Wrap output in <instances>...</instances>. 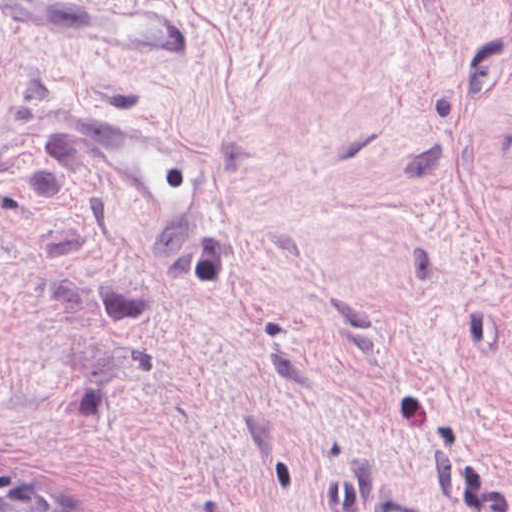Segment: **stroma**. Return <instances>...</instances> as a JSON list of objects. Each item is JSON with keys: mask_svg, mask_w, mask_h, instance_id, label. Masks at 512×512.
Segmentation results:
<instances>
[{"mask_svg": "<svg viewBox=\"0 0 512 512\" xmlns=\"http://www.w3.org/2000/svg\"><path fill=\"white\" fill-rule=\"evenodd\" d=\"M192 60L0 14V462L79 512H512V0H155ZM215 155L153 243L56 107Z\"/></svg>", "mask_w": 512, "mask_h": 512, "instance_id": "1", "label": "stroma"}]
</instances>
